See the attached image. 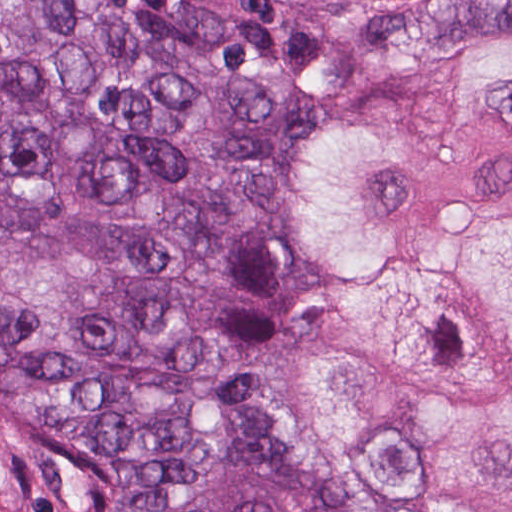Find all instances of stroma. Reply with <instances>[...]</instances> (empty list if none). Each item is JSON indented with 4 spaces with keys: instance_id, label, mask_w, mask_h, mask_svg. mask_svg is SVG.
I'll use <instances>...</instances> for the list:
<instances>
[{
    "instance_id": "stroma-1",
    "label": "stroma",
    "mask_w": 512,
    "mask_h": 512,
    "mask_svg": "<svg viewBox=\"0 0 512 512\" xmlns=\"http://www.w3.org/2000/svg\"><path fill=\"white\" fill-rule=\"evenodd\" d=\"M1 1L0 0V512H92L85 472L51 423L1 404ZM176 42L225 63L254 68L291 66L369 16L395 7L448 0H119ZM512 41V31L480 30L430 48L402 70L385 75L294 129L280 147L270 190L243 249L232 301V363L265 422L307 463L376 512H404L356 490L341 474L278 430L258 406L246 357V322L271 216L274 179L286 150L314 127L355 111L371 88L391 84L448 60L483 54ZM365 103V102H364ZM363 103V104H364ZM363 104L359 107L361 108Z\"/></svg>"
}]
</instances>
